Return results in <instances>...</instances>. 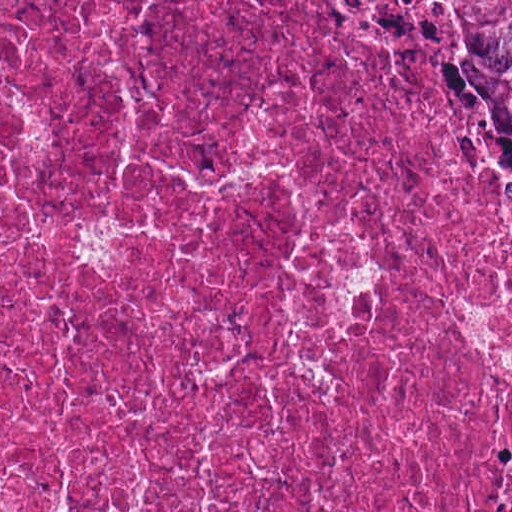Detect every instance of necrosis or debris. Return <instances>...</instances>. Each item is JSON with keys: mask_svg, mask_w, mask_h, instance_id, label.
I'll list each match as a JSON object with an SVG mask.
<instances>
[{"mask_svg": "<svg viewBox=\"0 0 512 512\" xmlns=\"http://www.w3.org/2000/svg\"><path fill=\"white\" fill-rule=\"evenodd\" d=\"M0 512H512V229L364 0H0Z\"/></svg>", "mask_w": 512, "mask_h": 512, "instance_id": "necrosis-or-debris-1", "label": "necrosis or debris"}]
</instances>
